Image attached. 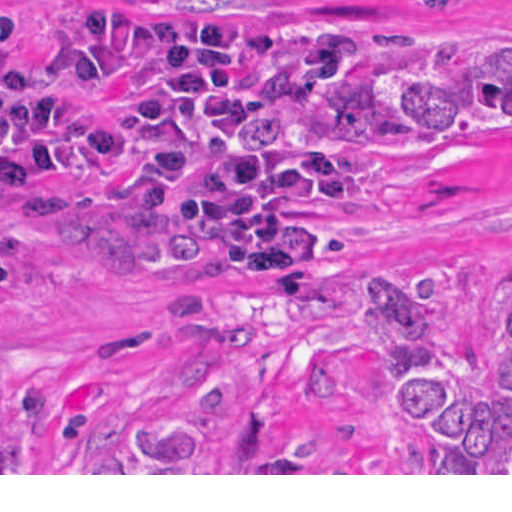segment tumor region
Returning <instances> with one entry per match:
<instances>
[{
  "mask_svg": "<svg viewBox=\"0 0 512 512\" xmlns=\"http://www.w3.org/2000/svg\"><path fill=\"white\" fill-rule=\"evenodd\" d=\"M458 11L480 0H414ZM313 91L278 130L285 147H343L361 157L400 153L459 125L512 115V70H412ZM475 296L451 266L396 282H366V337L309 353L300 368L311 411L301 446L267 450L271 409L240 407L237 447L212 444L230 356L206 348L176 356L197 400L186 411L111 438L86 473H512V282L492 300L484 359L464 362L457 329ZM0 473H20V448L0 418Z\"/></svg>",
  "mask_w": 512,
  "mask_h": 512,
  "instance_id": "obj_1",
  "label": "tumor region"
}]
</instances>
